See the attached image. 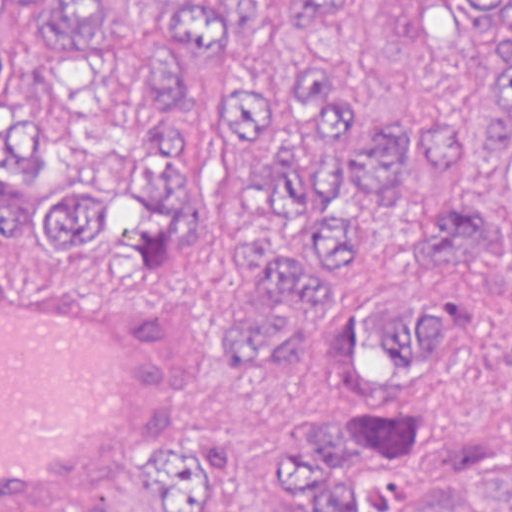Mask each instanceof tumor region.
<instances>
[{
    "label": "tumor region",
    "mask_w": 512,
    "mask_h": 512,
    "mask_svg": "<svg viewBox=\"0 0 512 512\" xmlns=\"http://www.w3.org/2000/svg\"><path fill=\"white\" fill-rule=\"evenodd\" d=\"M361 0H0V255L52 265L109 250L138 281L197 265L213 226L205 97L235 145L224 355L290 353L327 281L347 286L346 371L383 390L421 376L430 319L370 294L382 219L415 224L421 269L512 267V0H441L433 45L460 80L453 119L389 115L338 67L331 29ZM406 417L369 406L300 416L279 456L282 512H512V451L460 457L422 494ZM231 447L171 443L67 512H229Z\"/></svg>",
    "instance_id": "1"
}]
</instances>
